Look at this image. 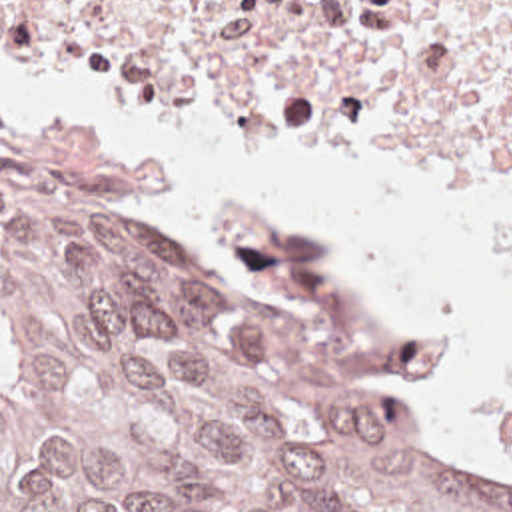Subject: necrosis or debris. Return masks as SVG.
<instances>
[{
    "instance_id": "1",
    "label": "necrosis or debris",
    "mask_w": 512,
    "mask_h": 512,
    "mask_svg": "<svg viewBox=\"0 0 512 512\" xmlns=\"http://www.w3.org/2000/svg\"><path fill=\"white\" fill-rule=\"evenodd\" d=\"M0 48L180 120L449 162L512 246V0H0Z\"/></svg>"
}]
</instances>
